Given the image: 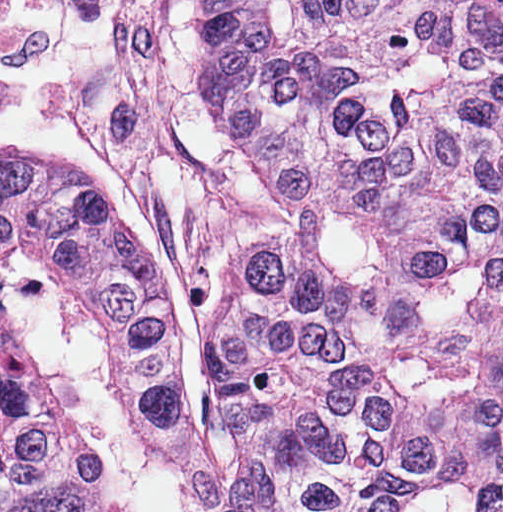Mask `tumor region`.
Wrapping results in <instances>:
<instances>
[{"instance_id":"obj_1","label":"tumor region","mask_w":512,"mask_h":512,"mask_svg":"<svg viewBox=\"0 0 512 512\" xmlns=\"http://www.w3.org/2000/svg\"><path fill=\"white\" fill-rule=\"evenodd\" d=\"M186 401L178 286L148 229L64 159L0 142V512H375L253 247Z\"/></svg>"}]
</instances>
